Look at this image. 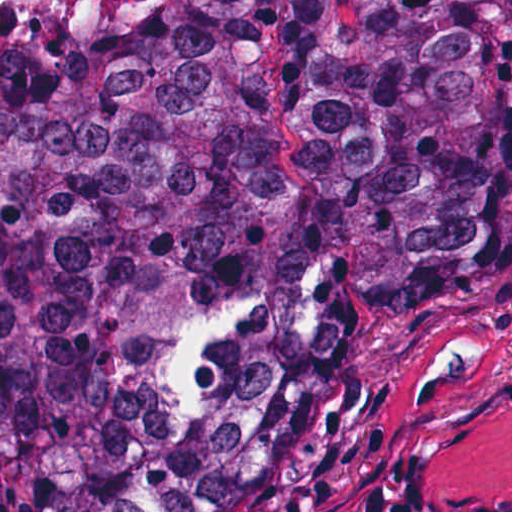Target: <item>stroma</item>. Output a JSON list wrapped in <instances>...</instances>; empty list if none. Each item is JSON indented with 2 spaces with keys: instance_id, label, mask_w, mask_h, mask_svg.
<instances>
[{
  "instance_id": "35a3bbf8",
  "label": "stroma",
  "mask_w": 512,
  "mask_h": 512,
  "mask_svg": "<svg viewBox=\"0 0 512 512\" xmlns=\"http://www.w3.org/2000/svg\"><path fill=\"white\" fill-rule=\"evenodd\" d=\"M462 330L512 347V224L441 307L357 344L315 442L257 512H512V368L458 365L417 388Z\"/></svg>"
}]
</instances>
